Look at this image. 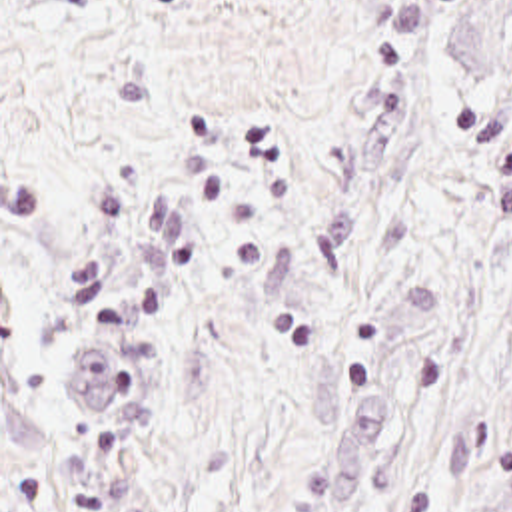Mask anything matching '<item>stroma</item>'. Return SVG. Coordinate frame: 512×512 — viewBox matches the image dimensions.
Returning <instances> with one entry per match:
<instances>
[{
	"label": "stroma",
	"mask_w": 512,
	"mask_h": 512,
	"mask_svg": "<svg viewBox=\"0 0 512 512\" xmlns=\"http://www.w3.org/2000/svg\"><path fill=\"white\" fill-rule=\"evenodd\" d=\"M0 512H512V0H0Z\"/></svg>",
	"instance_id": "35a3bbf8"
}]
</instances>
